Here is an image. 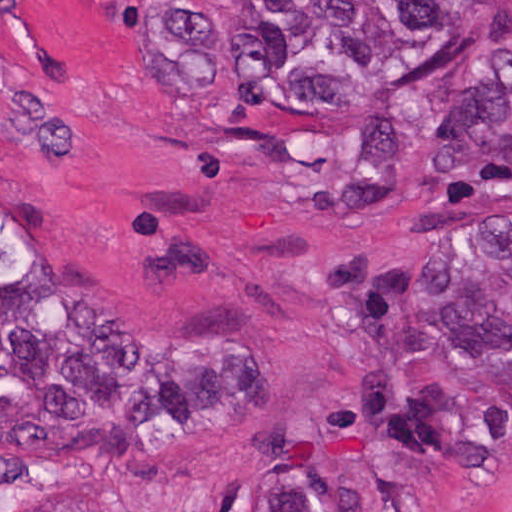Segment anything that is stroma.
Returning <instances> with one entry per match:
<instances>
[{
	"label": "stroma",
	"mask_w": 512,
	"mask_h": 512,
	"mask_svg": "<svg viewBox=\"0 0 512 512\" xmlns=\"http://www.w3.org/2000/svg\"><path fill=\"white\" fill-rule=\"evenodd\" d=\"M204 0H0V512H330L447 401L432 512H512V374L426 304L512 228V7L384 103H244Z\"/></svg>",
	"instance_id": "1"
}]
</instances>
